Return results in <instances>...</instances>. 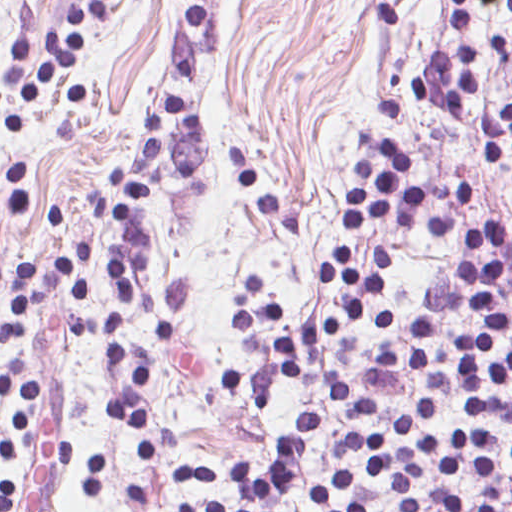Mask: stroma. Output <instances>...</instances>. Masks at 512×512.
<instances>
[{"mask_svg": "<svg viewBox=\"0 0 512 512\" xmlns=\"http://www.w3.org/2000/svg\"><path fill=\"white\" fill-rule=\"evenodd\" d=\"M68 2L0 0V318L9 315L14 260L33 262L45 290V303L30 310L29 331L0 344V423L18 448V462L0 465V484L12 481L14 512H185L198 497L238 504L231 486L170 484V462L222 467L241 457L265 471L341 385L364 389L376 414L329 412L282 512H312L308 493L333 482L338 438L397 430L427 399L438 404L437 416L396 444L411 449L467 425L488 433L492 463L512 475V418L472 413L461 394L431 391L437 361L461 332L481 326L479 317L440 329L427 372L408 362L421 292L456 279L465 259L508 263L496 277L508 335L487 361L512 349V180L484 164L480 133L477 139L483 110L512 101V22L493 7L472 11L483 73L469 116L439 114L411 87L413 74L452 54V17L436 0H211L209 37L187 33L193 0H125L118 17L90 28L87 103L66 102V79L37 102L10 97L2 72L19 9L33 4L27 33L36 38L66 32ZM164 89L197 97L210 145L191 179H178L143 208L153 241L136 282L180 279L191 291L173 345L153 337L141 310L127 314L130 354L151 362L145 387L157 449L145 462L140 444L103 413L100 402L120 390V380L101 339L95 330L63 338L59 317L67 311L50 303L69 292L57 274L66 251L93 245L85 310L106 315L114 233L92 192L112 188L119 162L142 156L141 119ZM381 136L413 154L407 176L427 196L430 216H453L467 229L500 223L504 242L465 250L384 220L341 236L351 164ZM354 241L359 263L371 247L390 255L389 288L369 315L393 310L403 326L312 352L295 380L275 384L266 405L251 408L221 380L250 365L234 305L238 279L271 281L294 327L307 328L335 307L322 267ZM372 506L402 512L386 478Z\"/></svg>", "mask_w": 512, "mask_h": 512, "instance_id": "35a3bbf8", "label": "stroma"}]
</instances>
